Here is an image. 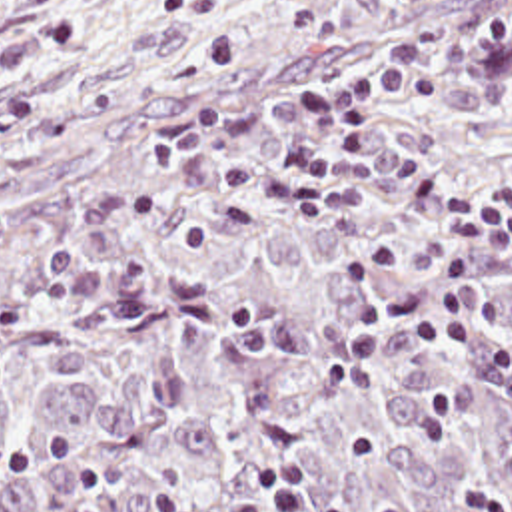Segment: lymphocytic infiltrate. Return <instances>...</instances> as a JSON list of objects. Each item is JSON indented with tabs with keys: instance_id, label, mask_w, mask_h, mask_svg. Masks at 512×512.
<instances>
[{
	"instance_id": "1",
	"label": "lymphocytic infiltrate",
	"mask_w": 512,
	"mask_h": 512,
	"mask_svg": "<svg viewBox=\"0 0 512 512\" xmlns=\"http://www.w3.org/2000/svg\"><path fill=\"white\" fill-rule=\"evenodd\" d=\"M476 47H512V17L434 31L374 69L274 103L288 121L262 155L250 147L264 119L232 123V111L218 95L186 105L144 149L158 165L172 145L206 151V191L194 219L178 233L184 255L202 251L220 233L256 231L260 219L244 201L250 193L272 195L300 217L328 225L356 213L360 189L384 187L410 213L438 227L442 239L422 251L436 275L410 289L384 287L406 255L396 239L340 263L338 277L354 317L316 368L326 386H370L378 382V341L392 335L410 341L418 360L422 448L440 446L458 412L454 386L436 370L448 349L470 355L478 374L512 398V337L482 299L484 257L512 265V215L436 183L400 149L356 125L348 109L352 99L436 105L446 95L434 77L464 67ZM442 494L456 512H512V452L500 474L458 476ZM148 496L158 512H328L312 480L280 464L246 472L238 494L218 504H200L168 480L150 484ZM392 512L418 510L394 506Z\"/></svg>"
}]
</instances>
